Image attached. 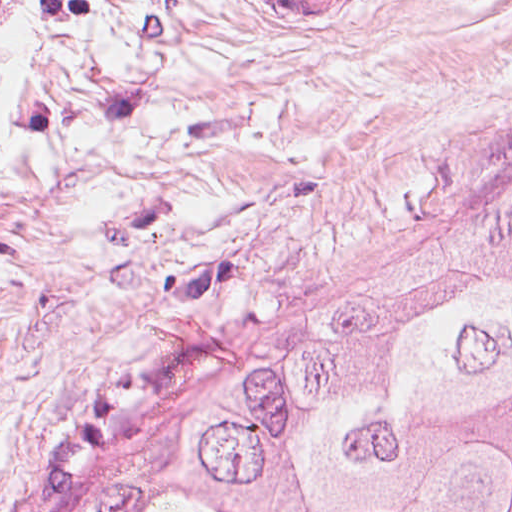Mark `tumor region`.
Returning <instances> with one entry per match:
<instances>
[{
    "mask_svg": "<svg viewBox=\"0 0 512 512\" xmlns=\"http://www.w3.org/2000/svg\"><path fill=\"white\" fill-rule=\"evenodd\" d=\"M77 512H512V219L272 384L137 441Z\"/></svg>",
    "mask_w": 512,
    "mask_h": 512,
    "instance_id": "obj_1",
    "label": "tumor region"
}]
</instances>
